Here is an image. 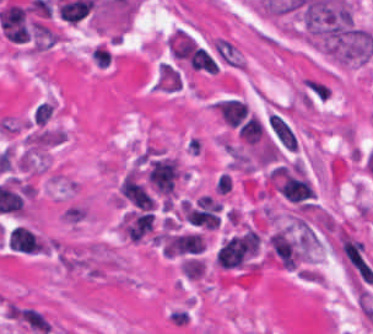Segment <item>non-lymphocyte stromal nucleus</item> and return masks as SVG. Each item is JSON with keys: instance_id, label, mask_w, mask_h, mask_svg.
Here are the masks:
<instances>
[{"instance_id": "dd21d789", "label": "non-lymphocyte stromal nucleus", "mask_w": 373, "mask_h": 334, "mask_svg": "<svg viewBox=\"0 0 373 334\" xmlns=\"http://www.w3.org/2000/svg\"><path fill=\"white\" fill-rule=\"evenodd\" d=\"M212 45L219 57L234 68H244L245 61L238 47L230 40L215 36L212 39Z\"/></svg>"}]
</instances>
